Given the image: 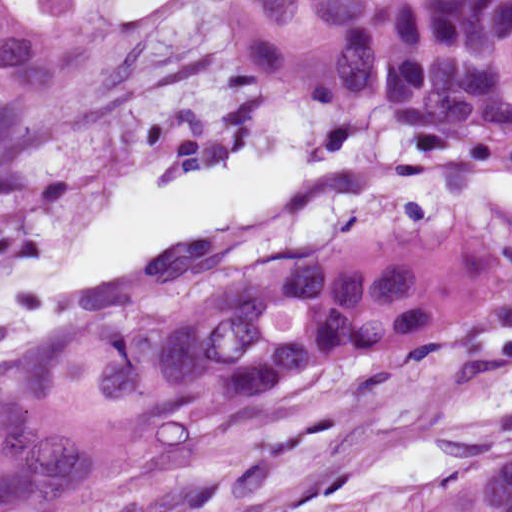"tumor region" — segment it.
<instances>
[{"instance_id":"obj_1","label":"tumor region","mask_w":512,"mask_h":512,"mask_svg":"<svg viewBox=\"0 0 512 512\" xmlns=\"http://www.w3.org/2000/svg\"><path fill=\"white\" fill-rule=\"evenodd\" d=\"M425 1L231 0L225 48L236 76L248 85L311 95L369 33ZM78 22L70 6L30 25L0 4V150L61 89ZM252 256L179 268L111 300L95 317L0 368Z\"/></svg>"}]
</instances>
